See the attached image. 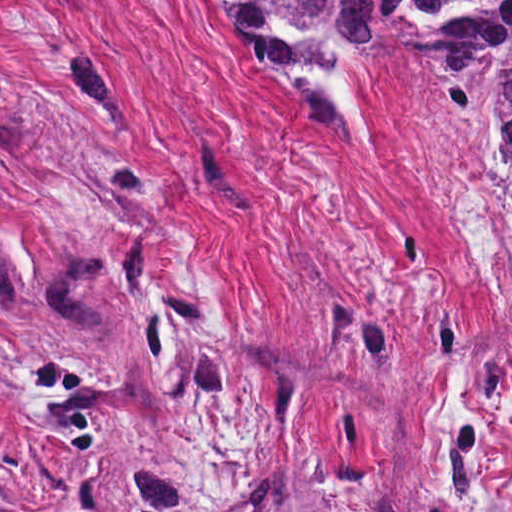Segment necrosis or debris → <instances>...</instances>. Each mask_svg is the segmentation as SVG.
<instances>
[{
    "mask_svg": "<svg viewBox=\"0 0 512 512\" xmlns=\"http://www.w3.org/2000/svg\"><path fill=\"white\" fill-rule=\"evenodd\" d=\"M420 144L479 293L512 327L511 192L489 163L443 140L421 111Z\"/></svg>",
    "mask_w": 512,
    "mask_h": 512,
    "instance_id": "obj_1",
    "label": "necrosis or debris"
}]
</instances>
